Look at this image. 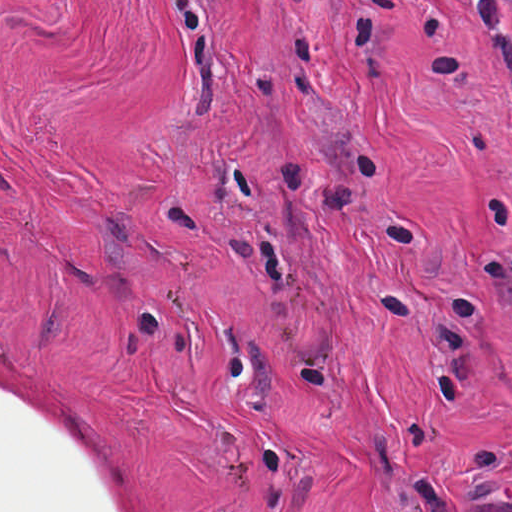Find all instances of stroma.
<instances>
[{
  "instance_id": "35a3bbf8",
  "label": "stroma",
  "mask_w": 512,
  "mask_h": 512,
  "mask_svg": "<svg viewBox=\"0 0 512 512\" xmlns=\"http://www.w3.org/2000/svg\"><path fill=\"white\" fill-rule=\"evenodd\" d=\"M512 500V102L466 0H289Z\"/></svg>"
}]
</instances>
